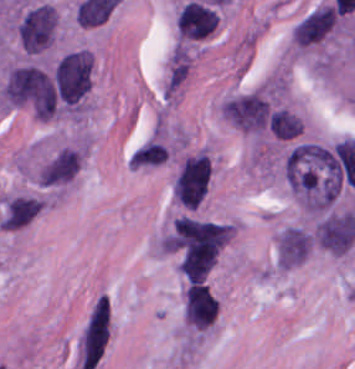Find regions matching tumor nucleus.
Returning <instances> with one entry per match:
<instances>
[{"instance_id": "c2bd9aea", "label": "tumor nucleus", "mask_w": 355, "mask_h": 369, "mask_svg": "<svg viewBox=\"0 0 355 369\" xmlns=\"http://www.w3.org/2000/svg\"><path fill=\"white\" fill-rule=\"evenodd\" d=\"M219 16L214 5L191 0L177 14L178 37L182 41H197L207 37L218 25Z\"/></svg>"}, {"instance_id": "3e47fb67", "label": "tumor nucleus", "mask_w": 355, "mask_h": 369, "mask_svg": "<svg viewBox=\"0 0 355 369\" xmlns=\"http://www.w3.org/2000/svg\"><path fill=\"white\" fill-rule=\"evenodd\" d=\"M79 162V148L67 145L39 167L38 181L44 186H60L73 179Z\"/></svg>"}, {"instance_id": "2083b535", "label": "tumor nucleus", "mask_w": 355, "mask_h": 369, "mask_svg": "<svg viewBox=\"0 0 355 369\" xmlns=\"http://www.w3.org/2000/svg\"><path fill=\"white\" fill-rule=\"evenodd\" d=\"M58 28L55 5L38 1L31 4L19 17L17 34L26 52L40 53L53 44Z\"/></svg>"}, {"instance_id": "5ab6c2c4", "label": "tumor nucleus", "mask_w": 355, "mask_h": 369, "mask_svg": "<svg viewBox=\"0 0 355 369\" xmlns=\"http://www.w3.org/2000/svg\"><path fill=\"white\" fill-rule=\"evenodd\" d=\"M1 93L11 107L38 119H50L59 109L49 71L28 62L16 64L8 71Z\"/></svg>"}, {"instance_id": "feef74b5", "label": "tumor nucleus", "mask_w": 355, "mask_h": 369, "mask_svg": "<svg viewBox=\"0 0 355 369\" xmlns=\"http://www.w3.org/2000/svg\"><path fill=\"white\" fill-rule=\"evenodd\" d=\"M336 16L331 1L314 6L295 22L291 33L293 42L306 47L319 42L333 30Z\"/></svg>"}, {"instance_id": "8087334f", "label": "tumor nucleus", "mask_w": 355, "mask_h": 369, "mask_svg": "<svg viewBox=\"0 0 355 369\" xmlns=\"http://www.w3.org/2000/svg\"><path fill=\"white\" fill-rule=\"evenodd\" d=\"M183 313L193 329L204 330L213 324L218 314V299L205 282H186Z\"/></svg>"}, {"instance_id": "f7901128", "label": "tumor nucleus", "mask_w": 355, "mask_h": 369, "mask_svg": "<svg viewBox=\"0 0 355 369\" xmlns=\"http://www.w3.org/2000/svg\"><path fill=\"white\" fill-rule=\"evenodd\" d=\"M169 148L160 138H152L132 150L129 157L131 165L156 166L164 163Z\"/></svg>"}, {"instance_id": "2f306a5c", "label": "tumor nucleus", "mask_w": 355, "mask_h": 369, "mask_svg": "<svg viewBox=\"0 0 355 369\" xmlns=\"http://www.w3.org/2000/svg\"><path fill=\"white\" fill-rule=\"evenodd\" d=\"M350 165V140H299L284 161L287 183L300 206L322 212L340 194Z\"/></svg>"}, {"instance_id": "8643909e", "label": "tumor nucleus", "mask_w": 355, "mask_h": 369, "mask_svg": "<svg viewBox=\"0 0 355 369\" xmlns=\"http://www.w3.org/2000/svg\"><path fill=\"white\" fill-rule=\"evenodd\" d=\"M229 236L230 224L183 215L175 219L165 239V248L182 274L204 278Z\"/></svg>"}, {"instance_id": "2cbd58db", "label": "tumor nucleus", "mask_w": 355, "mask_h": 369, "mask_svg": "<svg viewBox=\"0 0 355 369\" xmlns=\"http://www.w3.org/2000/svg\"><path fill=\"white\" fill-rule=\"evenodd\" d=\"M95 60L87 48L63 53L52 70L59 112H78L92 87Z\"/></svg>"}, {"instance_id": "268c6acd", "label": "tumor nucleus", "mask_w": 355, "mask_h": 369, "mask_svg": "<svg viewBox=\"0 0 355 369\" xmlns=\"http://www.w3.org/2000/svg\"><path fill=\"white\" fill-rule=\"evenodd\" d=\"M38 199V195L12 194L3 203L1 217L19 228Z\"/></svg>"}, {"instance_id": "3d1891a8", "label": "tumor nucleus", "mask_w": 355, "mask_h": 369, "mask_svg": "<svg viewBox=\"0 0 355 369\" xmlns=\"http://www.w3.org/2000/svg\"><path fill=\"white\" fill-rule=\"evenodd\" d=\"M212 174V160L205 153L186 155L173 178V199L183 207H197L209 190Z\"/></svg>"}]
</instances>
